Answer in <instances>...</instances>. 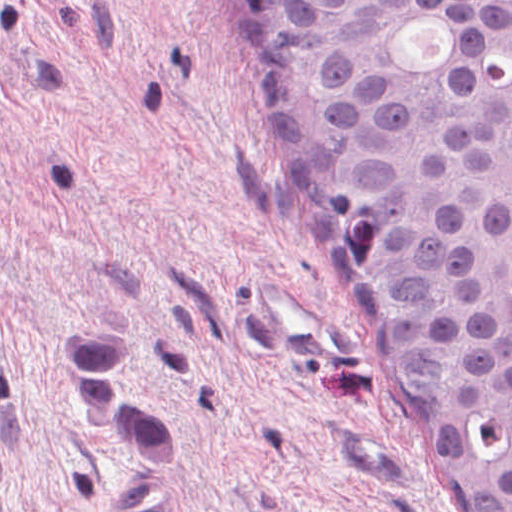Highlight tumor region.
<instances>
[{"mask_svg": "<svg viewBox=\"0 0 512 512\" xmlns=\"http://www.w3.org/2000/svg\"><path fill=\"white\" fill-rule=\"evenodd\" d=\"M275 193L464 512H512V0H231ZM131 326L51 354L106 449L163 475L123 375Z\"/></svg>", "mask_w": 512, "mask_h": 512, "instance_id": "tumor-region-1", "label": "tumor region"}]
</instances>
